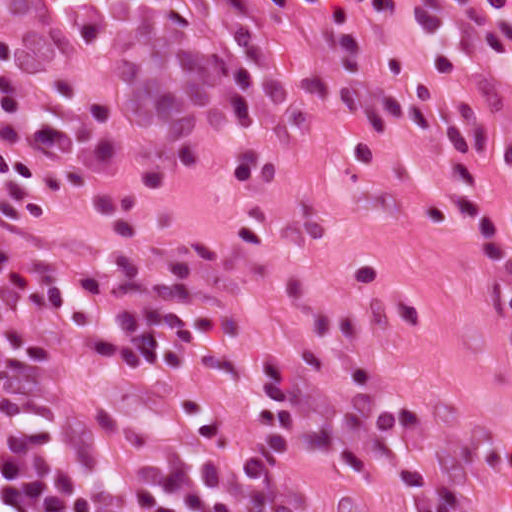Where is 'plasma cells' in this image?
<instances>
[{"label": "plasma cells", "mask_w": 512, "mask_h": 512, "mask_svg": "<svg viewBox=\"0 0 512 512\" xmlns=\"http://www.w3.org/2000/svg\"><path fill=\"white\" fill-rule=\"evenodd\" d=\"M88 68L112 77L134 123L175 146L213 125L314 112L398 127L428 149L451 147L457 200L505 279L512 313V217L502 230L486 163L512 172V122L489 135L504 90L498 0H66ZM21 49L0 36V218L30 229L55 220L57 193L83 198L100 229L137 238L166 176L128 191L110 112L55 82L72 110L30 112L14 86ZM221 348L212 302L147 270L95 264L29 274L0 262V512H296L303 452L373 455L400 410L386 383L338 349H306L262 366L248 436L198 422L136 424L68 406L77 377L147 369L190 372ZM408 512H453L436 497Z\"/></svg>", "instance_id": "obj_1"}]
</instances>
